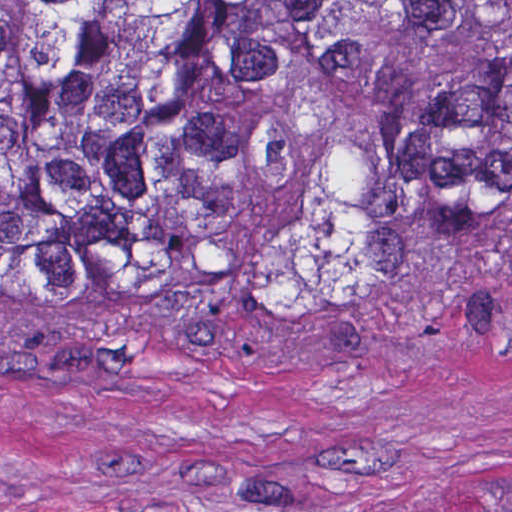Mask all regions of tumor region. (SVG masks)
Returning a JSON list of instances; mask_svg holds the SVG:
<instances>
[{"instance_id": "1", "label": "tumor region", "mask_w": 512, "mask_h": 512, "mask_svg": "<svg viewBox=\"0 0 512 512\" xmlns=\"http://www.w3.org/2000/svg\"><path fill=\"white\" fill-rule=\"evenodd\" d=\"M469 291H512V0H0V301Z\"/></svg>"}]
</instances>
